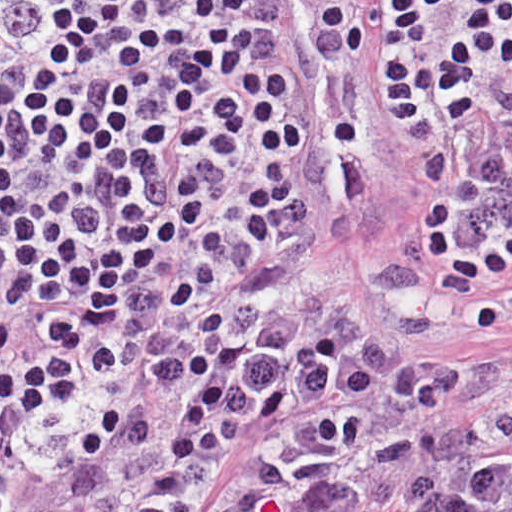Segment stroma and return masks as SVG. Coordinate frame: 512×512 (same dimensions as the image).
Segmentation results:
<instances>
[{
  "label": "stroma",
  "instance_id": "35a3bbf8",
  "mask_svg": "<svg viewBox=\"0 0 512 512\" xmlns=\"http://www.w3.org/2000/svg\"><path fill=\"white\" fill-rule=\"evenodd\" d=\"M273 1L276 39L293 56L282 2ZM289 100L304 126L305 150L301 165L287 179L300 182L311 201L307 125L294 60ZM394 133L399 169L366 238L339 253L315 209L312 227L298 240L253 239L216 261L124 377L100 372L92 359L80 397L60 416L39 470L14 512H51L91 478L81 467L79 449L84 433L111 405L121 406L123 427L132 426L142 435L168 433L211 390L280 372L306 358L333 322L338 305H358L355 282L396 271L394 235L405 141ZM117 320L118 311L110 327ZM392 335L408 341L413 353L451 362L472 379L471 392L449 403L445 415L465 418L512 402V327ZM357 402L317 396L277 416L251 420L211 462L184 512H219L226 481L256 450Z\"/></svg>",
  "mask_w": 512,
  "mask_h": 512
}]
</instances>
